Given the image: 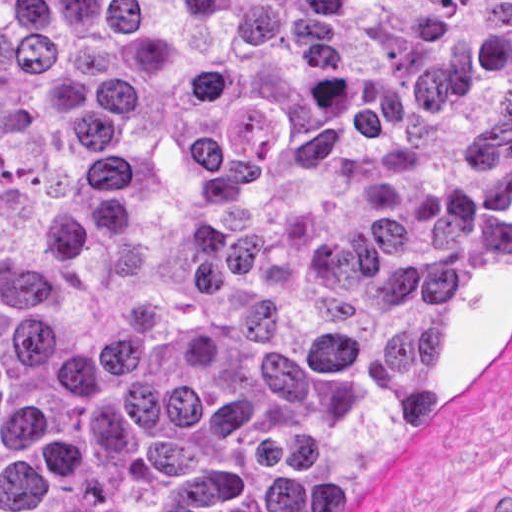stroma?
Returning a JSON list of instances; mask_svg holds the SVG:
<instances>
[{"instance_id":"stroma-1","label":"stroma","mask_w":512,"mask_h":512,"mask_svg":"<svg viewBox=\"0 0 512 512\" xmlns=\"http://www.w3.org/2000/svg\"><path fill=\"white\" fill-rule=\"evenodd\" d=\"M436 370L442 421L364 479L341 512H480L498 486L512 485V243L451 306L436 341Z\"/></svg>"}]
</instances>
